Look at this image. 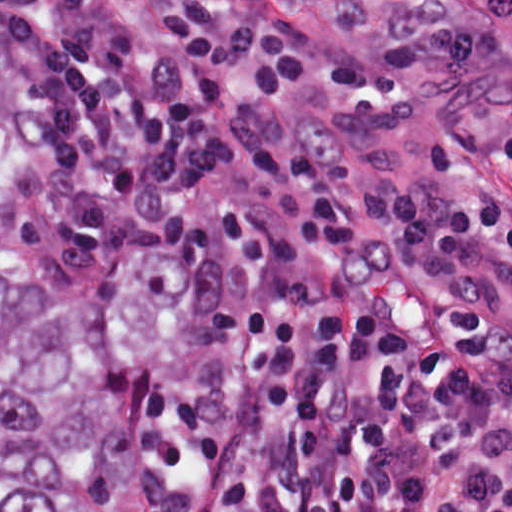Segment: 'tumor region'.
Instances as JSON below:
<instances>
[{"label": "tumor region", "instance_id": "1", "mask_svg": "<svg viewBox=\"0 0 512 512\" xmlns=\"http://www.w3.org/2000/svg\"><path fill=\"white\" fill-rule=\"evenodd\" d=\"M37 129L0 77V512H148L127 434L130 386L186 317L189 275L164 252L102 265L41 321L16 308L2 210Z\"/></svg>", "mask_w": 512, "mask_h": 512}]
</instances>
